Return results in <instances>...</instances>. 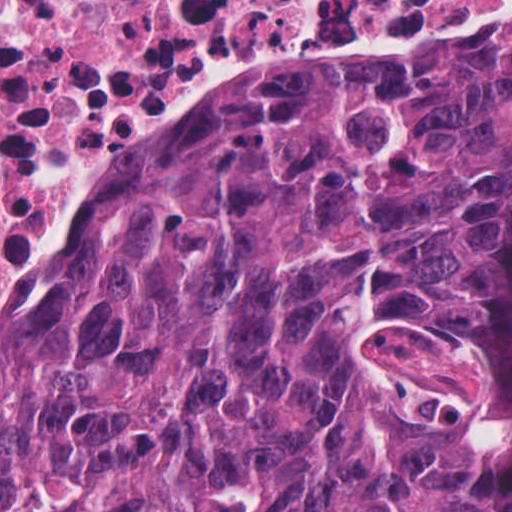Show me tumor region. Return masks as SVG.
I'll return each instance as SVG.
<instances>
[{"label":"tumor region","instance_id":"obj_1","mask_svg":"<svg viewBox=\"0 0 512 512\" xmlns=\"http://www.w3.org/2000/svg\"><path fill=\"white\" fill-rule=\"evenodd\" d=\"M512 51L208 108L0 313V512H483Z\"/></svg>","mask_w":512,"mask_h":512}]
</instances>
